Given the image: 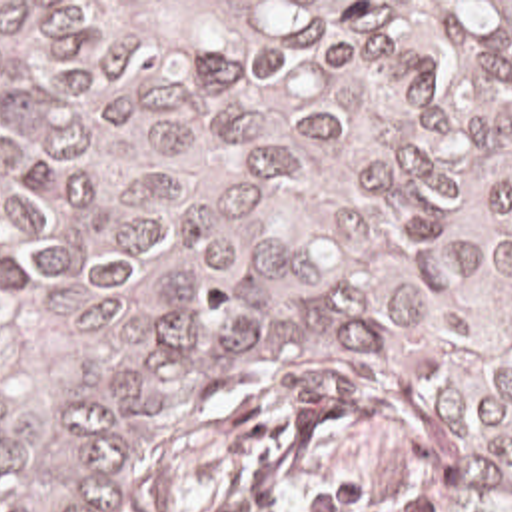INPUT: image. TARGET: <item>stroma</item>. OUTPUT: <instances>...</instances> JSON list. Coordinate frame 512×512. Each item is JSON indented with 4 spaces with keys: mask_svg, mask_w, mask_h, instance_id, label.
Here are the masks:
<instances>
[{
    "mask_svg": "<svg viewBox=\"0 0 512 512\" xmlns=\"http://www.w3.org/2000/svg\"><path fill=\"white\" fill-rule=\"evenodd\" d=\"M0 2H512V0H0ZM402 423L342 375L286 371L142 447V512H320L374 473Z\"/></svg>",
    "mask_w": 512,
    "mask_h": 512,
    "instance_id": "35a3bbf8",
    "label": "stroma"
}]
</instances>
